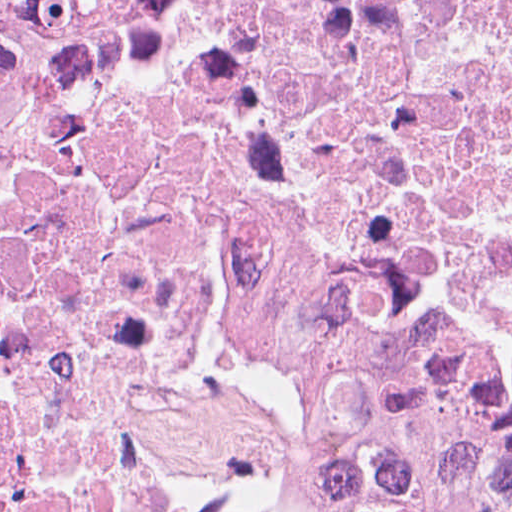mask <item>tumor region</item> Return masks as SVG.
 <instances>
[{"label": "tumor region", "mask_w": 512, "mask_h": 512, "mask_svg": "<svg viewBox=\"0 0 512 512\" xmlns=\"http://www.w3.org/2000/svg\"><path fill=\"white\" fill-rule=\"evenodd\" d=\"M165 0H0V129L117 69Z\"/></svg>", "instance_id": "tumor-region-1"}]
</instances>
